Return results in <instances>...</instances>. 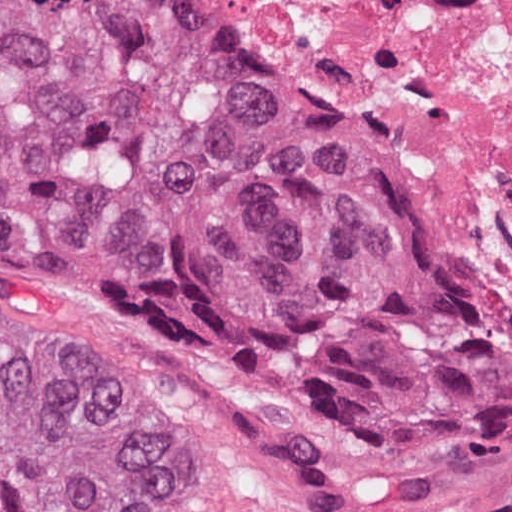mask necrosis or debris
<instances>
[{
	"mask_svg": "<svg viewBox=\"0 0 512 512\" xmlns=\"http://www.w3.org/2000/svg\"><path fill=\"white\" fill-rule=\"evenodd\" d=\"M407 179L512 355V0H220Z\"/></svg>",
	"mask_w": 512,
	"mask_h": 512,
	"instance_id": "1",
	"label": "necrosis or debris"
}]
</instances>
